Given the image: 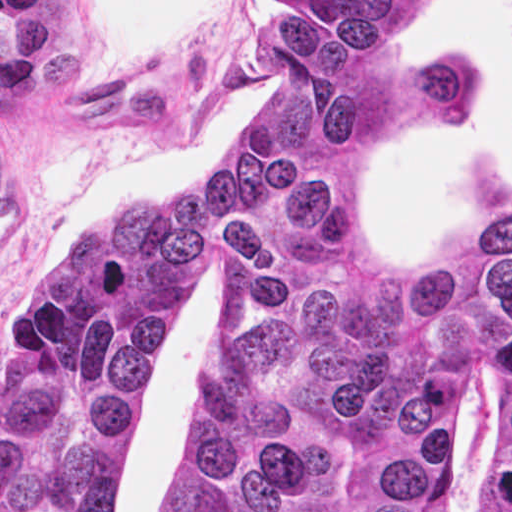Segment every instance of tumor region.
Returning <instances> with one entry per match:
<instances>
[{"mask_svg":"<svg viewBox=\"0 0 512 512\" xmlns=\"http://www.w3.org/2000/svg\"><path fill=\"white\" fill-rule=\"evenodd\" d=\"M416 1L271 0L241 143L50 256L0 362V512H121L200 248L230 317L167 512H452L468 372H498L484 512H512V202L434 266L385 251L359 211L394 134L487 105L473 54L389 40Z\"/></svg>","mask_w":512,"mask_h":512,"instance_id":"e687c5a6","label":"tumor region"}]
</instances>
